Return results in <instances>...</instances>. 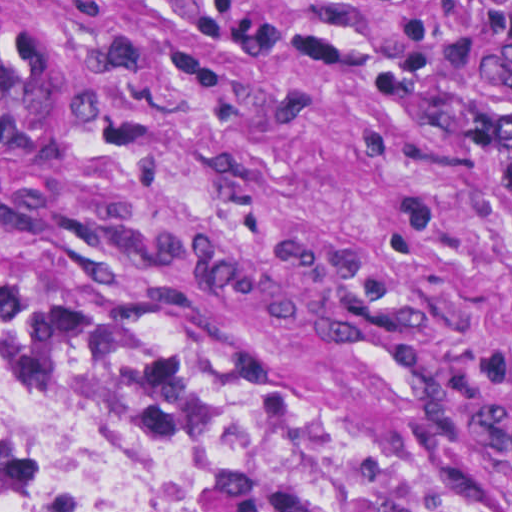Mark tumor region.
<instances>
[{
  "instance_id": "tumor-region-1",
  "label": "tumor region",
  "mask_w": 512,
  "mask_h": 512,
  "mask_svg": "<svg viewBox=\"0 0 512 512\" xmlns=\"http://www.w3.org/2000/svg\"><path fill=\"white\" fill-rule=\"evenodd\" d=\"M157 67L145 37L0 14V163L69 177L104 99ZM0 371L79 389L125 421V452L84 493L57 499L0 477V512H480L444 479L277 395L118 343L0 322Z\"/></svg>"
}]
</instances>
